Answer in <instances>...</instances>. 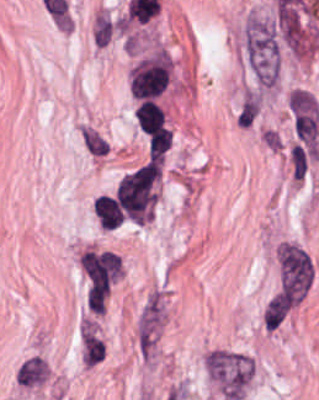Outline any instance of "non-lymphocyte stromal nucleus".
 <instances>
[{"label": "non-lymphocyte stromal nucleus", "instance_id": "non-lymphocyte-stromal-nucleus-1", "mask_svg": "<svg viewBox=\"0 0 319 400\" xmlns=\"http://www.w3.org/2000/svg\"><path fill=\"white\" fill-rule=\"evenodd\" d=\"M158 181L157 163L147 162L117 183L116 199L125 218L145 223L153 213Z\"/></svg>", "mask_w": 319, "mask_h": 400}, {"label": "non-lymphocyte stromal nucleus", "instance_id": "non-lymphocyte-stromal-nucleus-2", "mask_svg": "<svg viewBox=\"0 0 319 400\" xmlns=\"http://www.w3.org/2000/svg\"><path fill=\"white\" fill-rule=\"evenodd\" d=\"M209 374L229 400H239L254 376V360L247 354L213 349L208 357Z\"/></svg>", "mask_w": 319, "mask_h": 400}, {"label": "non-lymphocyte stromal nucleus", "instance_id": "non-lymphocyte-stromal-nucleus-3", "mask_svg": "<svg viewBox=\"0 0 319 400\" xmlns=\"http://www.w3.org/2000/svg\"><path fill=\"white\" fill-rule=\"evenodd\" d=\"M163 317L162 304L159 294H151L146 299L137 323V343L143 354L149 355Z\"/></svg>", "mask_w": 319, "mask_h": 400}, {"label": "non-lymphocyte stromal nucleus", "instance_id": "non-lymphocyte-stromal-nucleus-4", "mask_svg": "<svg viewBox=\"0 0 319 400\" xmlns=\"http://www.w3.org/2000/svg\"><path fill=\"white\" fill-rule=\"evenodd\" d=\"M46 374L47 369L44 360L30 357L17 367L15 382L22 386H36L42 384Z\"/></svg>", "mask_w": 319, "mask_h": 400}, {"label": "non-lymphocyte stromal nucleus", "instance_id": "non-lymphocyte-stromal-nucleus-5", "mask_svg": "<svg viewBox=\"0 0 319 400\" xmlns=\"http://www.w3.org/2000/svg\"><path fill=\"white\" fill-rule=\"evenodd\" d=\"M292 302L283 294L276 293L264 310L263 323L266 329H276L289 314Z\"/></svg>", "mask_w": 319, "mask_h": 400}, {"label": "non-lymphocyte stromal nucleus", "instance_id": "non-lymphocyte-stromal-nucleus-6", "mask_svg": "<svg viewBox=\"0 0 319 400\" xmlns=\"http://www.w3.org/2000/svg\"><path fill=\"white\" fill-rule=\"evenodd\" d=\"M80 344L84 364L89 368L104 360L102 342L90 328H83L80 334Z\"/></svg>", "mask_w": 319, "mask_h": 400}, {"label": "non-lymphocyte stromal nucleus", "instance_id": "non-lymphocyte-stromal-nucleus-7", "mask_svg": "<svg viewBox=\"0 0 319 400\" xmlns=\"http://www.w3.org/2000/svg\"><path fill=\"white\" fill-rule=\"evenodd\" d=\"M107 296L108 282L106 277L90 282L85 298L89 311L101 315L106 305Z\"/></svg>", "mask_w": 319, "mask_h": 400}, {"label": "non-lymphocyte stromal nucleus", "instance_id": "non-lymphocyte-stromal-nucleus-8", "mask_svg": "<svg viewBox=\"0 0 319 400\" xmlns=\"http://www.w3.org/2000/svg\"><path fill=\"white\" fill-rule=\"evenodd\" d=\"M291 177L303 178L307 170V153L300 143L293 142L287 154Z\"/></svg>", "mask_w": 319, "mask_h": 400}, {"label": "non-lymphocyte stromal nucleus", "instance_id": "non-lymphocyte-stromal-nucleus-9", "mask_svg": "<svg viewBox=\"0 0 319 400\" xmlns=\"http://www.w3.org/2000/svg\"><path fill=\"white\" fill-rule=\"evenodd\" d=\"M259 112L258 95H244L238 109L237 119L241 126L253 124Z\"/></svg>", "mask_w": 319, "mask_h": 400}, {"label": "non-lymphocyte stromal nucleus", "instance_id": "non-lymphocyte-stromal-nucleus-10", "mask_svg": "<svg viewBox=\"0 0 319 400\" xmlns=\"http://www.w3.org/2000/svg\"><path fill=\"white\" fill-rule=\"evenodd\" d=\"M83 141L90 153L94 156H104L107 152V145L105 141L99 137L95 132L82 126Z\"/></svg>", "mask_w": 319, "mask_h": 400}]
</instances>
